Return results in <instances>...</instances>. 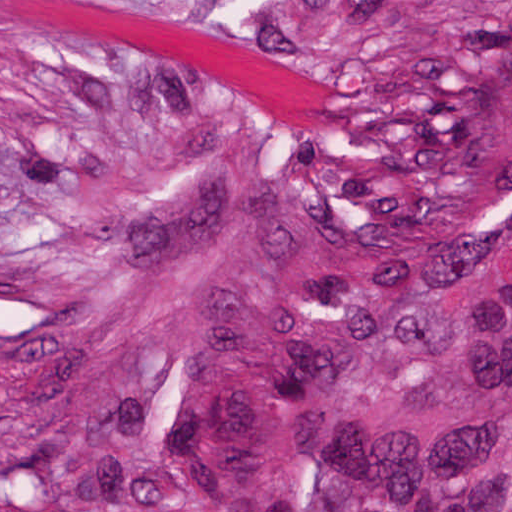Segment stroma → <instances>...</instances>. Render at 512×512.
Instances as JSON below:
<instances>
[{"label":"stroma","mask_w":512,"mask_h":512,"mask_svg":"<svg viewBox=\"0 0 512 512\" xmlns=\"http://www.w3.org/2000/svg\"><path fill=\"white\" fill-rule=\"evenodd\" d=\"M383 2L0 0V512L1 329L140 209L250 168H352L329 98Z\"/></svg>","instance_id":"obj_1"}]
</instances>
